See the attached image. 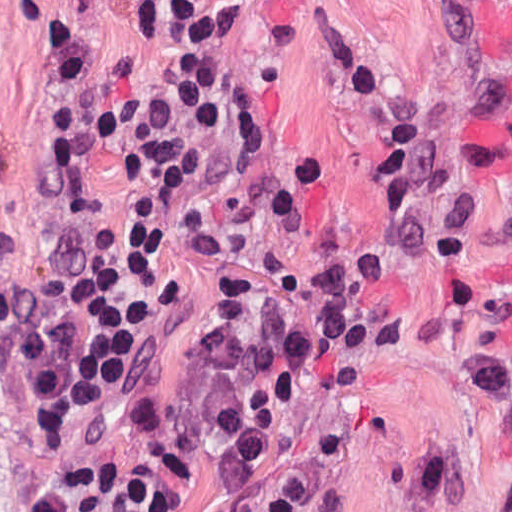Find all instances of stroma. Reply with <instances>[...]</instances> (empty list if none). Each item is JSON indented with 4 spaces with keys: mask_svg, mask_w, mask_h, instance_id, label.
<instances>
[{
    "mask_svg": "<svg viewBox=\"0 0 512 512\" xmlns=\"http://www.w3.org/2000/svg\"><path fill=\"white\" fill-rule=\"evenodd\" d=\"M47 1L168 0H0V512H29L93 449L127 458L139 512H437L417 505L410 488L412 449L426 441L452 450L474 482L512 486V430L488 415L466 358L468 333L435 301L428 270L413 258L390 270L410 339L393 352L353 350L319 410L232 504L203 509L185 500L137 447L170 346L202 303L207 259L235 245L305 261L313 245L270 216L224 211L237 83L261 87L276 140L330 154L349 235L368 241L387 214L368 182L373 149L327 59L326 35L335 28L365 42L396 102L427 113L512 76V0H211L214 115L170 213L144 305L85 400L51 421L26 422L13 398L22 352L93 250L66 131L72 59ZM433 161L467 179L483 215H499L503 229L475 246L471 267L476 283L512 310V113L440 139Z\"/></svg>",
    "mask_w": 512,
    "mask_h": 512,
    "instance_id": "1",
    "label": "stroma"
}]
</instances>
